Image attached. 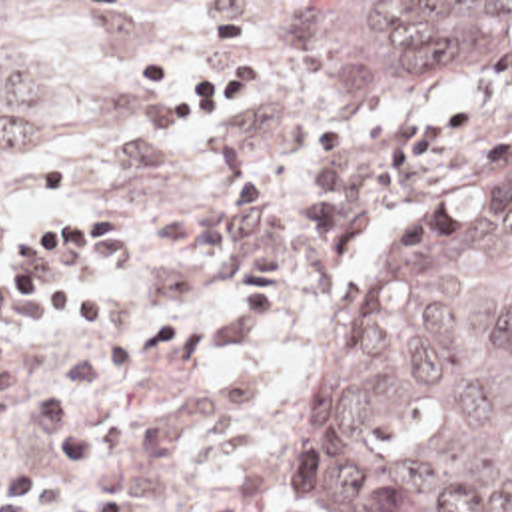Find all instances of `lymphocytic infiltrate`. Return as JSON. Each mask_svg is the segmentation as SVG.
Wrapping results in <instances>:
<instances>
[{"instance_id": "f902f5d3", "label": "lymphocytic infiltrate", "mask_w": 512, "mask_h": 512, "mask_svg": "<svg viewBox=\"0 0 512 512\" xmlns=\"http://www.w3.org/2000/svg\"><path fill=\"white\" fill-rule=\"evenodd\" d=\"M131 236L129 206H99L79 218H57L39 254H25L9 268L17 302L41 306L45 323L61 337H89L115 312L93 264L113 254ZM83 262L85 266H57ZM61 315L63 319H57ZM139 493L127 479L81 499L39 503L27 489L13 491L1 512H137Z\"/></svg>"}]
</instances>
